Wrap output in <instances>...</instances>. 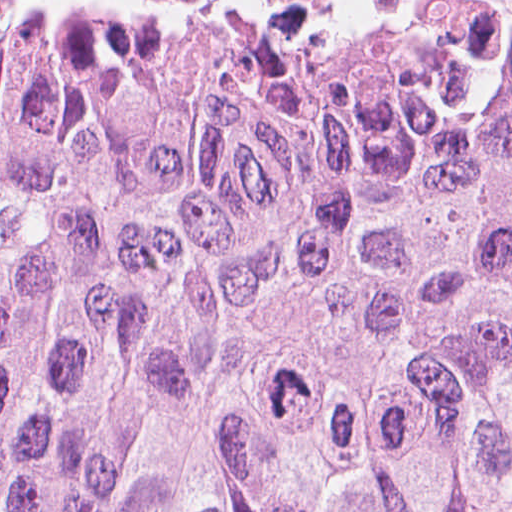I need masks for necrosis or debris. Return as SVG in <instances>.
I'll return each mask as SVG.
<instances>
[{
    "label": "necrosis or debris",
    "instance_id": "1",
    "mask_svg": "<svg viewBox=\"0 0 512 512\" xmlns=\"http://www.w3.org/2000/svg\"><path fill=\"white\" fill-rule=\"evenodd\" d=\"M175 10H421L459 0H141Z\"/></svg>",
    "mask_w": 512,
    "mask_h": 512
}]
</instances>
